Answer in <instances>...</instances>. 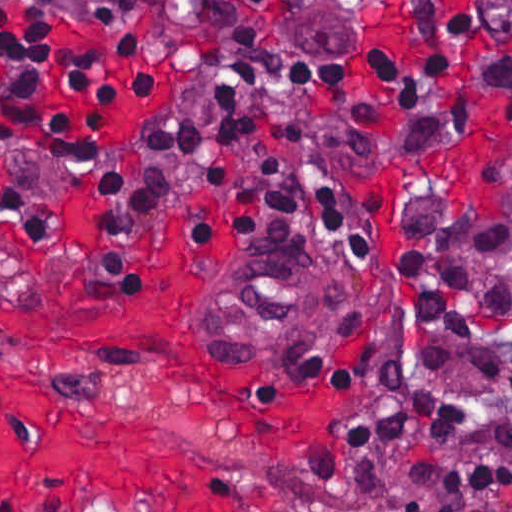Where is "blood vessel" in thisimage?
Wrapping results in <instances>:
<instances>
[{"label": "blood vessel", "instance_id": "8fb6f2fc", "mask_svg": "<svg viewBox=\"0 0 512 512\" xmlns=\"http://www.w3.org/2000/svg\"><path fill=\"white\" fill-rule=\"evenodd\" d=\"M285 239L237 253L214 275L210 315L222 338L243 348H304L327 337L345 291L339 264Z\"/></svg>", "mask_w": 512, "mask_h": 512}]
</instances>
